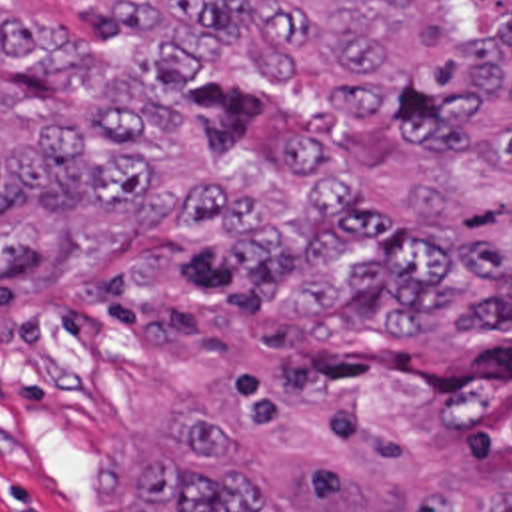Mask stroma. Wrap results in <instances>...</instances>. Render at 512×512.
Segmentation results:
<instances>
[{"label":"stroma","mask_w":512,"mask_h":512,"mask_svg":"<svg viewBox=\"0 0 512 512\" xmlns=\"http://www.w3.org/2000/svg\"><path fill=\"white\" fill-rule=\"evenodd\" d=\"M125 39L109 0H47ZM271 127L357 129L299 95L195 119L219 157ZM441 341L293 323L177 239L167 209L69 245L0 247V512H131L137 468L191 420L223 426L267 512H413L449 488L467 512L512 490L439 450ZM129 450L133 478L129 474Z\"/></svg>","instance_id":"1"}]
</instances>
